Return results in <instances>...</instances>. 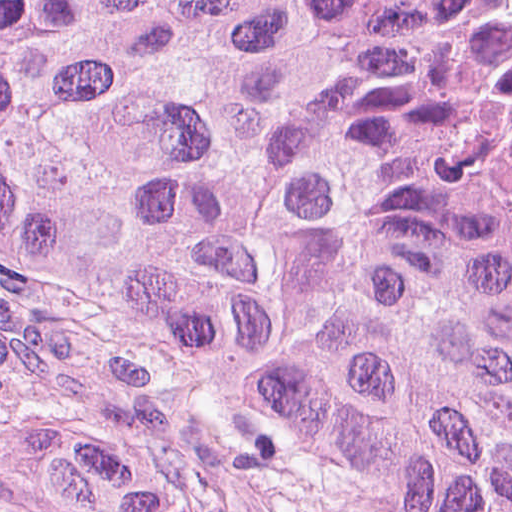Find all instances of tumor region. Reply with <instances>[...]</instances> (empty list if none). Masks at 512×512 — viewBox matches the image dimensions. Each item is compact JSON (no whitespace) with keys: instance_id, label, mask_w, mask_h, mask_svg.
Instances as JSON below:
<instances>
[{"instance_id":"tumor-region-1","label":"tumor region","mask_w":512,"mask_h":512,"mask_svg":"<svg viewBox=\"0 0 512 512\" xmlns=\"http://www.w3.org/2000/svg\"><path fill=\"white\" fill-rule=\"evenodd\" d=\"M0 249L294 512H512V0H0Z\"/></svg>"}]
</instances>
